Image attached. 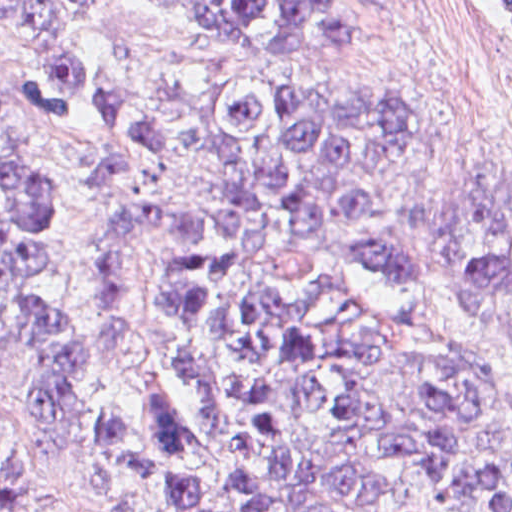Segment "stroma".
<instances>
[{
  "label": "stroma",
  "mask_w": 512,
  "mask_h": 512,
  "mask_svg": "<svg viewBox=\"0 0 512 512\" xmlns=\"http://www.w3.org/2000/svg\"><path fill=\"white\" fill-rule=\"evenodd\" d=\"M86 33L96 56L90 92L60 117L28 114L38 77L15 45L0 35V102L19 116L0 135L10 147L37 150L58 174L50 225V276L61 303L83 311L90 302V231L113 212L98 202L93 174L109 145L103 109L133 97L164 110L161 174L178 197L195 196L202 168L190 146L196 108L217 82H391L432 107L443 135L409 160L398 178V200L419 247V279L392 280L370 264L343 276L344 293L380 324L436 336L451 344L501 389L489 443L512 457V349L495 322L458 306L456 284L441 246L450 199L512 158V13L496 0H347L360 25L357 51L284 53L233 40L187 22L148 0H84ZM10 163L0 169V202ZM176 280V251L148 238L134 255L137 309L123 355L100 365L86 382V408L68 440L48 448L26 427L32 349L14 335L0 363V469L35 512H161L143 488L107 478L84 479L82 465L101 420L137 425L144 386L170 381L183 409L200 395L178 366L177 336L166 318Z\"/></svg>",
  "instance_id": "35a3bbf8"
}]
</instances>
